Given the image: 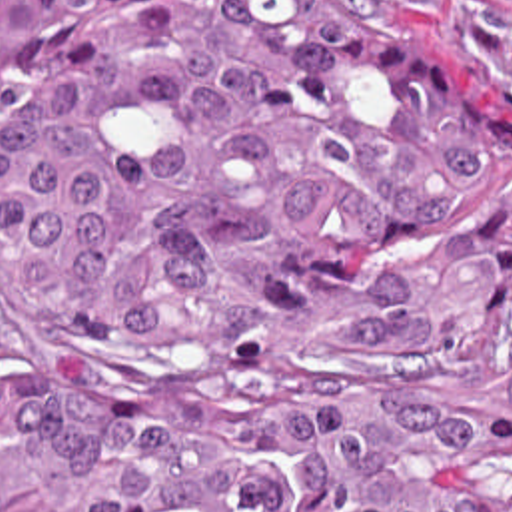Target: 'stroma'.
Wrapping results in <instances>:
<instances>
[{"label":"stroma","instance_id":"1","mask_svg":"<svg viewBox=\"0 0 512 512\" xmlns=\"http://www.w3.org/2000/svg\"><path fill=\"white\" fill-rule=\"evenodd\" d=\"M393 17L409 29L487 55L512 85V0H337Z\"/></svg>","mask_w":512,"mask_h":512}]
</instances>
